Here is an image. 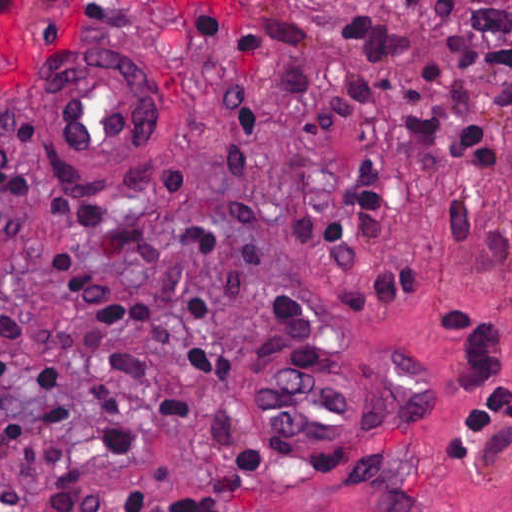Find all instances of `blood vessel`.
I'll return each instance as SVG.
<instances>
[{"instance_id": "blood-vessel-1", "label": "blood vessel", "mask_w": 512, "mask_h": 512, "mask_svg": "<svg viewBox=\"0 0 512 512\" xmlns=\"http://www.w3.org/2000/svg\"><path fill=\"white\" fill-rule=\"evenodd\" d=\"M139 48L77 46L55 58L44 104L52 175L84 193L119 190L157 152L155 94L134 62Z\"/></svg>"}]
</instances>
